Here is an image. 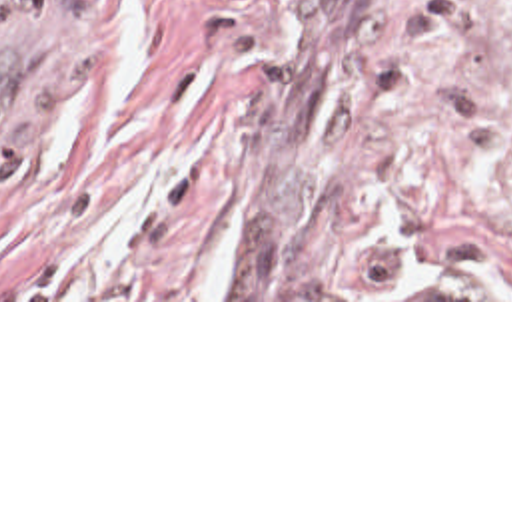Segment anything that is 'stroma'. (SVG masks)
<instances>
[{
  "mask_svg": "<svg viewBox=\"0 0 512 512\" xmlns=\"http://www.w3.org/2000/svg\"><path fill=\"white\" fill-rule=\"evenodd\" d=\"M0 302H512V0H0Z\"/></svg>",
  "mask_w": 512,
  "mask_h": 512,
  "instance_id": "obj_1",
  "label": "stroma"
}]
</instances>
